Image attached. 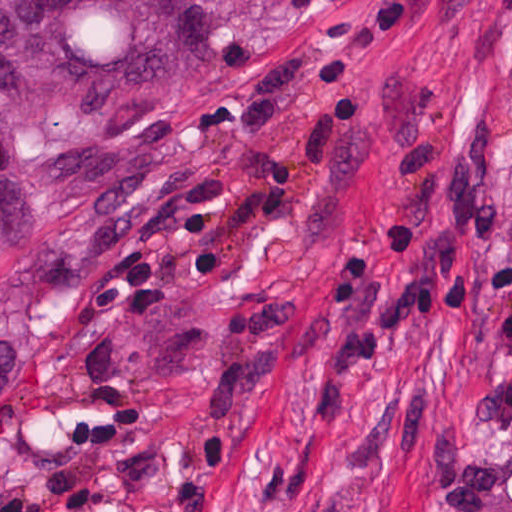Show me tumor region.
Instances as JSON below:
<instances>
[{"instance_id":"1","label":"tumor region","mask_w":512,"mask_h":512,"mask_svg":"<svg viewBox=\"0 0 512 512\" xmlns=\"http://www.w3.org/2000/svg\"><path fill=\"white\" fill-rule=\"evenodd\" d=\"M188 81L185 0H0V267L42 190L91 172L79 155L30 150L150 117Z\"/></svg>"}]
</instances>
